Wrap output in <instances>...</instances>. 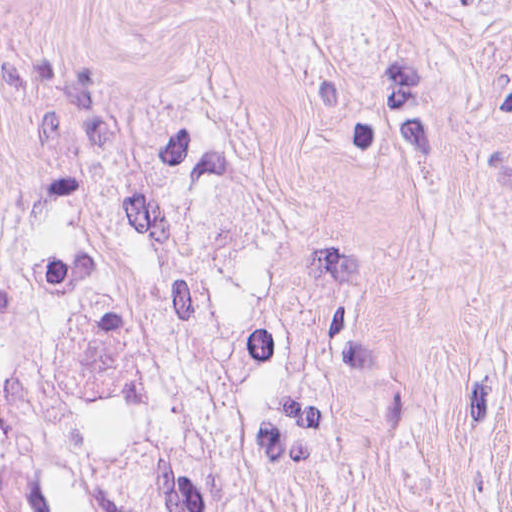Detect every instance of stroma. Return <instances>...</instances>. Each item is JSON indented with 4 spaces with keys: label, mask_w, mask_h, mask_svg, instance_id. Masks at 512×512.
Here are the masks:
<instances>
[{
    "label": "stroma",
    "mask_w": 512,
    "mask_h": 512,
    "mask_svg": "<svg viewBox=\"0 0 512 512\" xmlns=\"http://www.w3.org/2000/svg\"><path fill=\"white\" fill-rule=\"evenodd\" d=\"M168 137L264 201L305 512H512V0H0V209Z\"/></svg>",
    "instance_id": "35a3bbf8"
}]
</instances>
